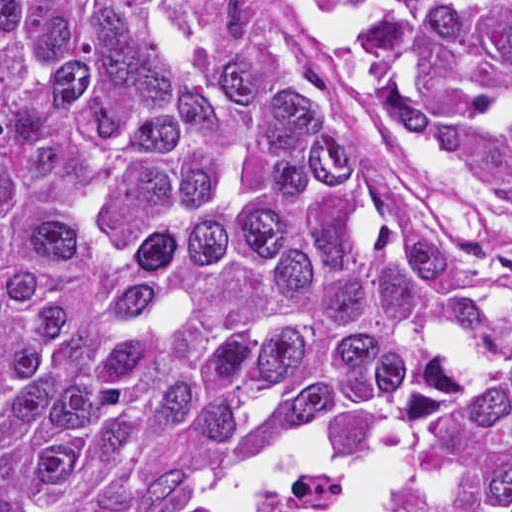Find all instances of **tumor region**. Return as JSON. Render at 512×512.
I'll return each mask as SVG.
<instances>
[{"instance_id": "tumor-region-1", "label": "tumor region", "mask_w": 512, "mask_h": 512, "mask_svg": "<svg viewBox=\"0 0 512 512\" xmlns=\"http://www.w3.org/2000/svg\"><path fill=\"white\" fill-rule=\"evenodd\" d=\"M0 512H512V1H0Z\"/></svg>"}]
</instances>
